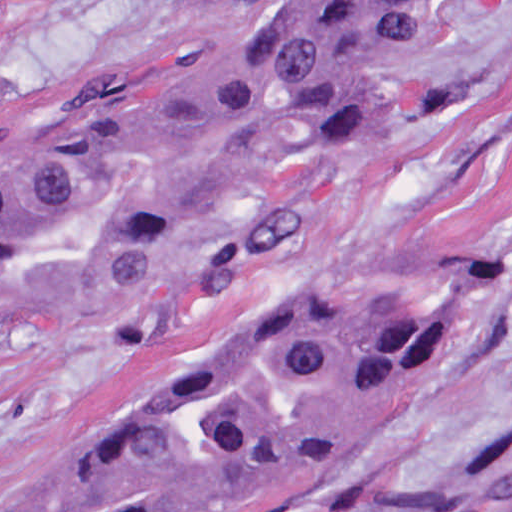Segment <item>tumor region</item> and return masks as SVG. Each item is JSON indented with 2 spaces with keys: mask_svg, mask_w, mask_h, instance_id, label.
<instances>
[{
  "mask_svg": "<svg viewBox=\"0 0 512 512\" xmlns=\"http://www.w3.org/2000/svg\"><path fill=\"white\" fill-rule=\"evenodd\" d=\"M437 0H223L268 21L264 66L310 133L383 149L378 76ZM253 122L191 45L136 49L0 114V324L68 285L222 260L227 308L142 362L113 403L28 464L0 512H232L269 497L395 402L432 350L397 298L296 303L216 252ZM482 354L512 364V317ZM388 512H512V406L481 457Z\"/></svg>",
  "mask_w": 512,
  "mask_h": 512,
  "instance_id": "e687c5a6",
  "label": "tumor region"
}]
</instances>
